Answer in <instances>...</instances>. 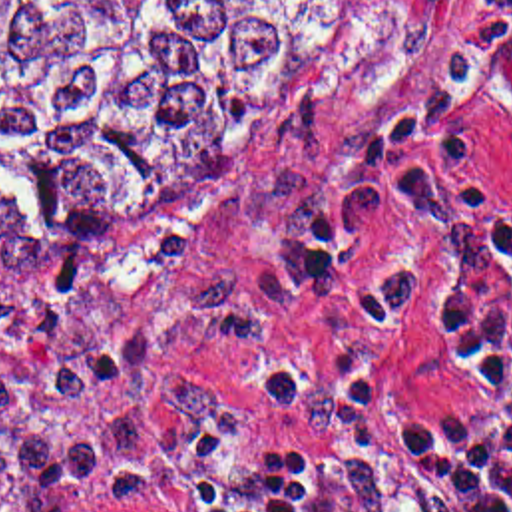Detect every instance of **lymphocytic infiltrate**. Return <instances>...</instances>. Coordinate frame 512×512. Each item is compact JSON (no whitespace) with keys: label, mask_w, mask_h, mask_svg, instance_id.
<instances>
[{"label":"lymphocytic infiltrate","mask_w":512,"mask_h":512,"mask_svg":"<svg viewBox=\"0 0 512 512\" xmlns=\"http://www.w3.org/2000/svg\"><path fill=\"white\" fill-rule=\"evenodd\" d=\"M512 75V0H475L461 39L374 119L314 199L302 231L308 284L342 292L354 255L391 211L425 229L417 263L352 310L393 328L429 306L475 418L429 432L391 430L393 446L445 512H512V199L483 153L473 93ZM115 504L147 512H338L326 486L288 456L196 434L147 470L49 488L11 512Z\"/></svg>","instance_id":"f902f5d3"}]
</instances>
